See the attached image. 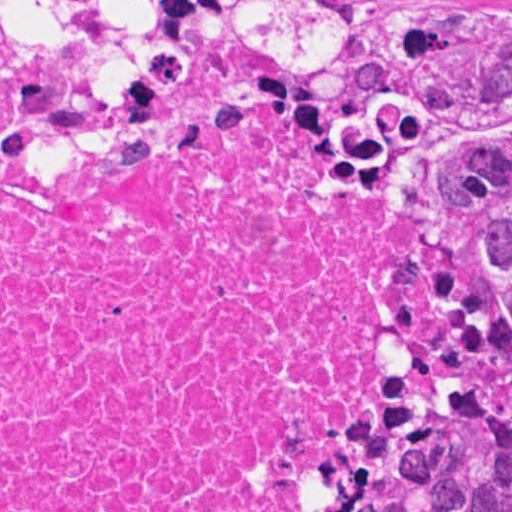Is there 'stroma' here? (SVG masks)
I'll return each mask as SVG.
<instances>
[{
    "mask_svg": "<svg viewBox=\"0 0 512 512\" xmlns=\"http://www.w3.org/2000/svg\"><path fill=\"white\" fill-rule=\"evenodd\" d=\"M336 1V0H335ZM394 0H367V34L366 40L378 27L385 9ZM461 1H499V0H461ZM14 11V10H13ZM333 67L331 69H335ZM468 301H469V197H468Z\"/></svg>",
    "mask_w": 512,
    "mask_h": 512,
    "instance_id": "obj_1",
    "label": "stroma"
}]
</instances>
